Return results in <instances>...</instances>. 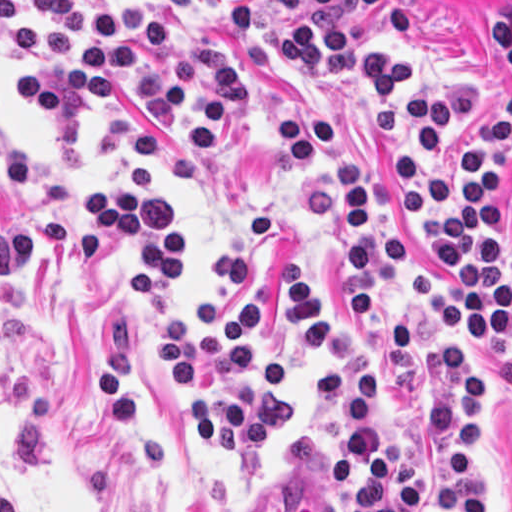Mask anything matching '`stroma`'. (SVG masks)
Instances as JSON below:
<instances>
[{
    "mask_svg": "<svg viewBox=\"0 0 512 512\" xmlns=\"http://www.w3.org/2000/svg\"><path fill=\"white\" fill-rule=\"evenodd\" d=\"M107 17L129 0H79ZM172 35L212 41L244 72L247 111L226 144L186 149L141 100L113 95L34 121L14 95L19 75L45 53L20 56L0 34V215H60L93 187L142 160L182 204L190 284L198 307L219 262L254 215H271V240L234 288L237 303L259 299L289 267L321 304L350 320L375 359L384 426L394 392L405 442L419 470V503L443 512L445 451L424 421L440 395V327L446 315L415 300L374 245V319L350 315L347 230L329 232L304 214V195L333 184L320 150L309 170L287 152L280 119L298 121L320 103L348 121L346 157L372 177V235L395 231L421 265L442 278L440 255L399 212L386 150L376 141L350 79L357 38L384 34L410 68L460 71L473 90L453 101V174L459 143L512 93V0H140ZM512 271V155L489 201ZM117 250L89 264L29 250L0 278V512H348L326 480L337 448L339 407H310L308 381L320 366L277 330L289 366L291 428L254 460L214 457L199 441L184 400L149 367L153 334L129 302ZM481 430L475 474L482 512H512V350L476 368Z\"/></svg>",
    "mask_w": 512,
    "mask_h": 512,
    "instance_id": "stroma-1",
    "label": "stroma"
}]
</instances>
